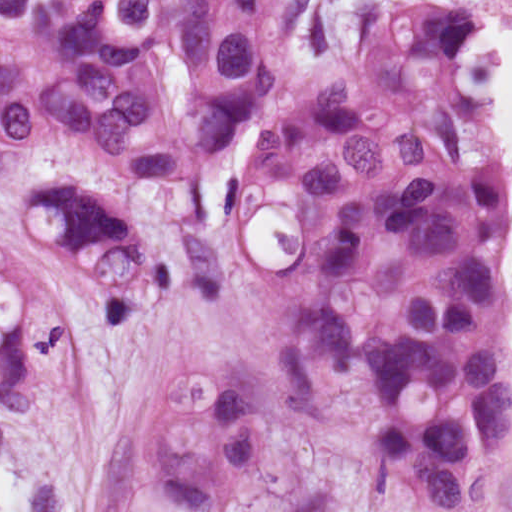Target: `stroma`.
I'll use <instances>...</instances> for the list:
<instances>
[{
    "mask_svg": "<svg viewBox=\"0 0 512 512\" xmlns=\"http://www.w3.org/2000/svg\"><path fill=\"white\" fill-rule=\"evenodd\" d=\"M418 4L462 3L404 0L375 8L319 65L301 61L295 46L301 5L292 35L296 82L223 149L207 175V225L195 224L185 180L118 176L89 148H37L14 170H0V251L41 276L71 318V354L54 400L31 423L12 421L0 405V512H105L118 457L153 386L176 368L226 365L256 386V466L242 494V512H512V424L486 502L474 510H439L389 484L371 463L324 442L301 419L279 377V339L291 296L273 291V278L292 268L301 251L295 209L272 202L238 224L216 208L226 178L238 171L240 150L298 95L324 91L352 72L380 22ZM41 181L99 185L138 241L172 266V291L137 323L113 326V292L79 276L34 234L25 201ZM505 209L511 240L500 272L509 303L512 379L508 197Z\"/></svg>",
    "mask_w": 512,
    "mask_h": 512,
    "instance_id": "obj_1",
    "label": "stroma"
}]
</instances>
